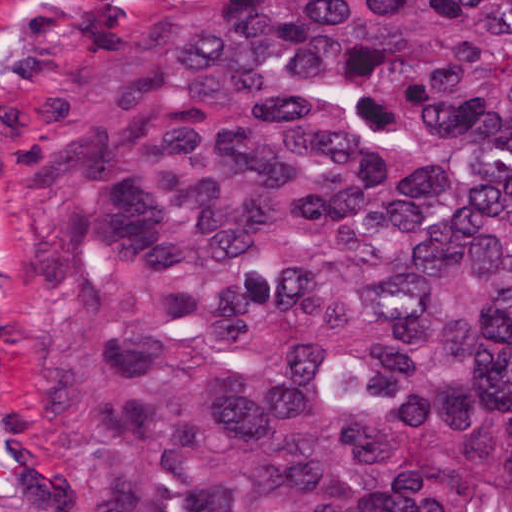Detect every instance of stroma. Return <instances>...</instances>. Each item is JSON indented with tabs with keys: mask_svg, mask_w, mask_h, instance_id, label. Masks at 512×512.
Listing matches in <instances>:
<instances>
[{
	"mask_svg": "<svg viewBox=\"0 0 512 512\" xmlns=\"http://www.w3.org/2000/svg\"><path fill=\"white\" fill-rule=\"evenodd\" d=\"M30 0H18V17ZM10 0H0V512H65L46 490L14 442L1 413V67L14 62Z\"/></svg>",
	"mask_w": 512,
	"mask_h": 512,
	"instance_id": "stroma-1",
	"label": "stroma"
}]
</instances>
